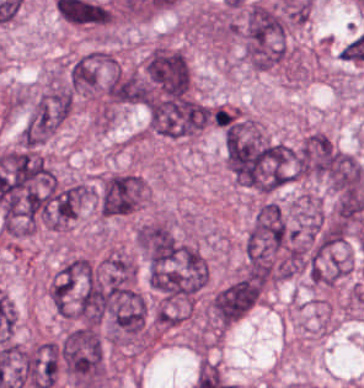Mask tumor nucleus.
<instances>
[{
	"instance_id": "5ab6c2c4",
	"label": "tumor nucleus",
	"mask_w": 364,
	"mask_h": 388,
	"mask_svg": "<svg viewBox=\"0 0 364 388\" xmlns=\"http://www.w3.org/2000/svg\"><path fill=\"white\" fill-rule=\"evenodd\" d=\"M62 367L82 387H97L106 379L105 349L95 327H76L61 340Z\"/></svg>"
},
{
	"instance_id": "c2bd9aea",
	"label": "tumor nucleus",
	"mask_w": 364,
	"mask_h": 388,
	"mask_svg": "<svg viewBox=\"0 0 364 388\" xmlns=\"http://www.w3.org/2000/svg\"><path fill=\"white\" fill-rule=\"evenodd\" d=\"M146 98L142 74L115 69L105 82V100L115 105H143Z\"/></svg>"
},
{
	"instance_id": "2cbd58db",
	"label": "tumor nucleus",
	"mask_w": 364,
	"mask_h": 388,
	"mask_svg": "<svg viewBox=\"0 0 364 388\" xmlns=\"http://www.w3.org/2000/svg\"><path fill=\"white\" fill-rule=\"evenodd\" d=\"M73 100V90L55 75L30 105L21 132L23 139H46L69 115Z\"/></svg>"
},
{
	"instance_id": "8087334f",
	"label": "tumor nucleus",
	"mask_w": 364,
	"mask_h": 388,
	"mask_svg": "<svg viewBox=\"0 0 364 388\" xmlns=\"http://www.w3.org/2000/svg\"><path fill=\"white\" fill-rule=\"evenodd\" d=\"M138 245L149 265L173 264L183 243L163 221H149L138 227Z\"/></svg>"
},
{
	"instance_id": "3d1891a8",
	"label": "tumor nucleus",
	"mask_w": 364,
	"mask_h": 388,
	"mask_svg": "<svg viewBox=\"0 0 364 388\" xmlns=\"http://www.w3.org/2000/svg\"><path fill=\"white\" fill-rule=\"evenodd\" d=\"M148 88L154 94L184 98L190 83V69L183 52L170 46L157 45L143 66Z\"/></svg>"
},
{
	"instance_id": "8643909e",
	"label": "tumor nucleus",
	"mask_w": 364,
	"mask_h": 388,
	"mask_svg": "<svg viewBox=\"0 0 364 388\" xmlns=\"http://www.w3.org/2000/svg\"><path fill=\"white\" fill-rule=\"evenodd\" d=\"M143 109L148 132L170 140L192 138L210 122L206 106L191 99L153 91Z\"/></svg>"
},
{
	"instance_id": "2f306a5c",
	"label": "tumor nucleus",
	"mask_w": 364,
	"mask_h": 388,
	"mask_svg": "<svg viewBox=\"0 0 364 388\" xmlns=\"http://www.w3.org/2000/svg\"><path fill=\"white\" fill-rule=\"evenodd\" d=\"M241 35L244 58L252 67H277L289 58V19L271 5L260 0L249 3Z\"/></svg>"
},
{
	"instance_id": "2083b535",
	"label": "tumor nucleus",
	"mask_w": 364,
	"mask_h": 388,
	"mask_svg": "<svg viewBox=\"0 0 364 388\" xmlns=\"http://www.w3.org/2000/svg\"><path fill=\"white\" fill-rule=\"evenodd\" d=\"M342 165L338 147L323 131L311 130L294 151L297 175L331 181Z\"/></svg>"
}]
</instances>
